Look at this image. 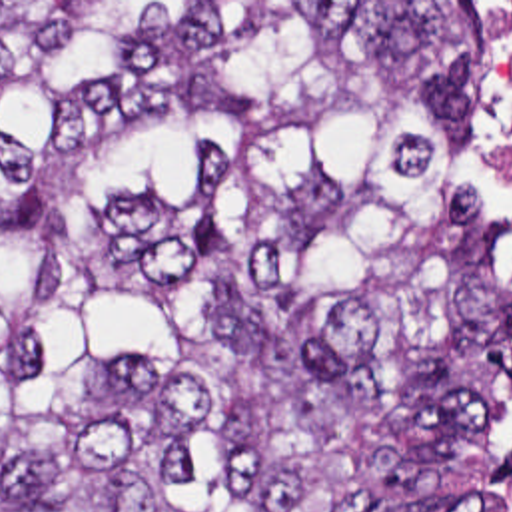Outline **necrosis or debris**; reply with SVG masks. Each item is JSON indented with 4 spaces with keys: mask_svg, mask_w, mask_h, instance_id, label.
<instances>
[{
    "mask_svg": "<svg viewBox=\"0 0 512 512\" xmlns=\"http://www.w3.org/2000/svg\"><path fill=\"white\" fill-rule=\"evenodd\" d=\"M485 28V162L497 218L512 232V2H479Z\"/></svg>",
    "mask_w": 512,
    "mask_h": 512,
    "instance_id": "obj_1",
    "label": "necrosis or debris"
}]
</instances>
